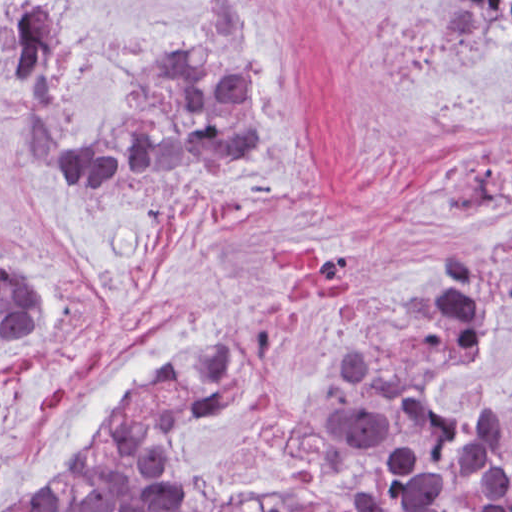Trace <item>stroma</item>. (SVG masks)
Here are the masks:
<instances>
[{
	"label": "stroma",
	"instance_id": "35a3bbf8",
	"mask_svg": "<svg viewBox=\"0 0 512 512\" xmlns=\"http://www.w3.org/2000/svg\"><path fill=\"white\" fill-rule=\"evenodd\" d=\"M9 1L55 3L75 134L207 32L221 1H249L260 158L236 174L134 166L107 187L33 178L2 80ZM434 1L512 0H0V252L48 295L46 318L0 346V512L74 468L114 408L207 327H247L208 485H274L365 324L512 223V33L475 48L435 37ZM511 402L512 306L441 408L479 421Z\"/></svg>",
	"mask_w": 512,
	"mask_h": 512
}]
</instances>
